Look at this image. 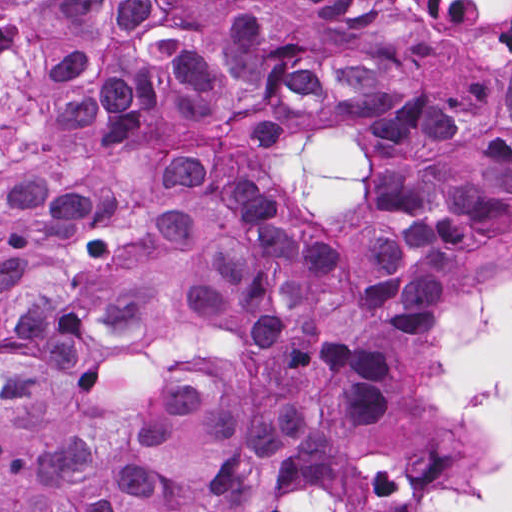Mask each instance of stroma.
<instances>
[{"label": "stroma", "mask_w": 512, "mask_h": 512, "mask_svg": "<svg viewBox=\"0 0 512 512\" xmlns=\"http://www.w3.org/2000/svg\"><path fill=\"white\" fill-rule=\"evenodd\" d=\"M252 15L271 23L277 44L322 78L286 97L246 135L227 140L231 161L257 187L256 207L291 234L331 250L353 244L387 194L389 144L373 125L331 118L346 93L338 65L397 62L428 87V103L478 98L505 73L512 51L493 50L468 73L431 78L420 65L427 46L372 0H113L112 27L99 77L102 126L79 148L44 152L0 174V192L47 183L90 198L108 229L111 173L139 143L128 88L149 83L224 21ZM512 282V244L477 271L456 277L431 304L414 347L400 360L452 415L460 472L473 465L477 433L436 396L433 353L445 310L479 287ZM446 479V478H445ZM444 480V479H442ZM442 480L427 493L434 498Z\"/></svg>", "instance_id": "35a3bbf8"}]
</instances>
